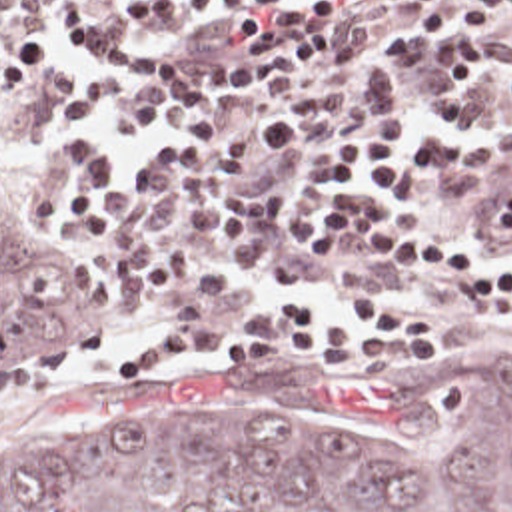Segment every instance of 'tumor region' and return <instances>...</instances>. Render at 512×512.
Returning a JSON list of instances; mask_svg holds the SVG:
<instances>
[{
	"label": "tumor region",
	"mask_w": 512,
	"mask_h": 512,
	"mask_svg": "<svg viewBox=\"0 0 512 512\" xmlns=\"http://www.w3.org/2000/svg\"><path fill=\"white\" fill-rule=\"evenodd\" d=\"M98 282L0 216V368L72 338ZM0 512H512V340L362 388L332 418L110 416L0 434Z\"/></svg>",
	"instance_id": "tumor-region-1"
}]
</instances>
